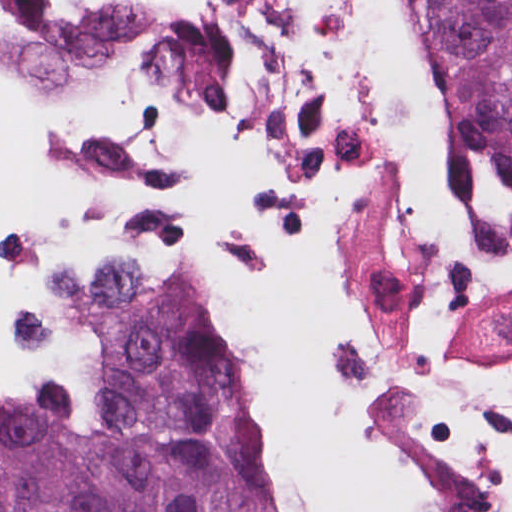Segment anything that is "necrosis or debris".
Returning a JSON list of instances; mask_svg holds the SVG:
<instances>
[{
  "label": "necrosis or debris",
  "instance_id": "obj_1",
  "mask_svg": "<svg viewBox=\"0 0 512 512\" xmlns=\"http://www.w3.org/2000/svg\"><path fill=\"white\" fill-rule=\"evenodd\" d=\"M0 246L208 294L290 512H512V280L418 0H0Z\"/></svg>",
  "mask_w": 512,
  "mask_h": 512
}]
</instances>
